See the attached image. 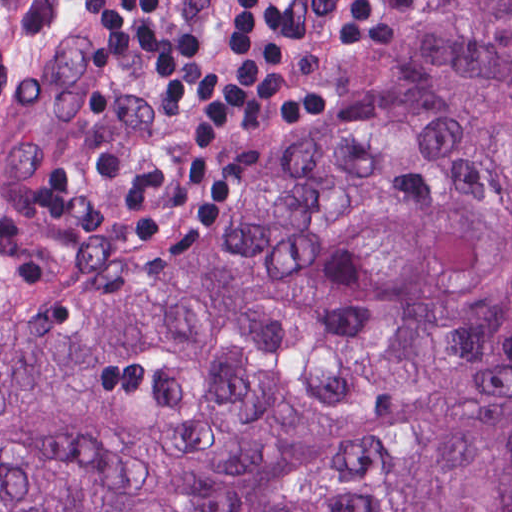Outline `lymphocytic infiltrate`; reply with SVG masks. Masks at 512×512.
<instances>
[{
	"instance_id": "f902f5d3",
	"label": "lymphocytic infiltrate",
	"mask_w": 512,
	"mask_h": 512,
	"mask_svg": "<svg viewBox=\"0 0 512 512\" xmlns=\"http://www.w3.org/2000/svg\"><path fill=\"white\" fill-rule=\"evenodd\" d=\"M95 44L84 65L152 69L149 97L194 111L189 125L129 156L93 141L27 181L49 221L130 237L157 252H192L225 225L241 190L276 149L340 102L330 91H287L280 52L305 42L381 47L396 26L374 0H231L229 61L204 66L197 33L161 0H76Z\"/></svg>"
}]
</instances>
